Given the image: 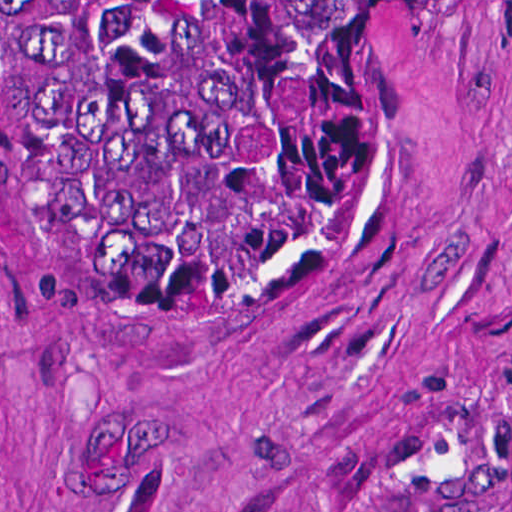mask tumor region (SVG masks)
Listing matches in <instances>:
<instances>
[{"instance_id":"e687c5a6","label":"tumor region","mask_w":512,"mask_h":512,"mask_svg":"<svg viewBox=\"0 0 512 512\" xmlns=\"http://www.w3.org/2000/svg\"><path fill=\"white\" fill-rule=\"evenodd\" d=\"M394 1L0 0L5 171L107 335L223 351L270 326Z\"/></svg>"}]
</instances>
